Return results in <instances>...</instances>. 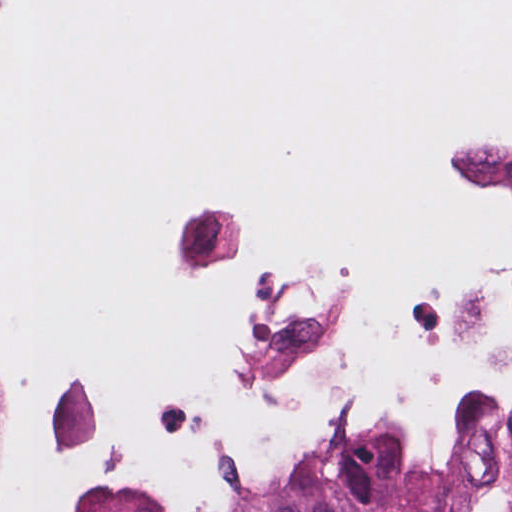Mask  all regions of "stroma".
<instances>
[{
    "label": "stroma",
    "instance_id": "stroma-1",
    "mask_svg": "<svg viewBox=\"0 0 512 512\" xmlns=\"http://www.w3.org/2000/svg\"><path fill=\"white\" fill-rule=\"evenodd\" d=\"M1 14V12H0ZM3 359H4V335L2 330V325L0 322V425H1V370L3 365ZM73 373H90L85 371H79V370H57L50 375L42 378L39 388L37 390L40 391L41 389L51 386L53 384H56L60 382L61 380L65 379L69 375ZM489 393H472L466 397H463L456 401V403L453 405V407L448 412L444 423L436 436L433 444L431 445L430 449L428 450L422 464H384L385 467L392 470L396 474L410 479L412 481L418 482L423 479L435 476L437 474L442 473L445 466L449 462L451 458V439H452V433H453V427L454 423L457 420L458 416L462 412L463 408L476 400L477 398L486 395ZM319 459L311 461L298 475L297 477L292 481V483L288 486L287 489L298 485L305 480H307L309 477H311L313 474H315L329 459ZM245 503H237L235 505L229 506L224 509L212 511V512H237V510ZM160 512H166L161 511Z\"/></svg>",
    "mask_w": 512,
    "mask_h": 512
}]
</instances>
